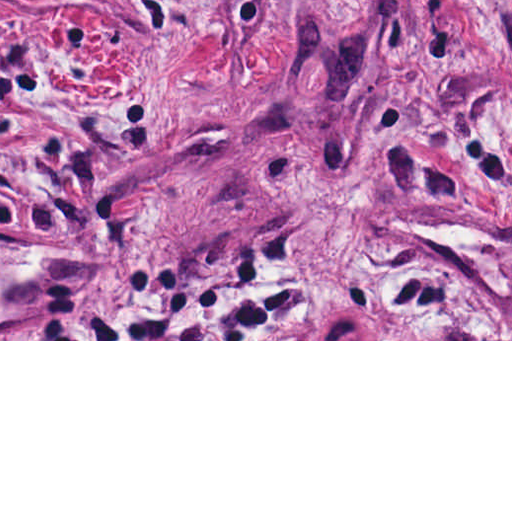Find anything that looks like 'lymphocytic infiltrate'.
I'll return each mask as SVG.
<instances>
[{"label":"lymphocytic infiltrate","mask_w":512,"mask_h":512,"mask_svg":"<svg viewBox=\"0 0 512 512\" xmlns=\"http://www.w3.org/2000/svg\"><path fill=\"white\" fill-rule=\"evenodd\" d=\"M73 339H294V307L282 284H191Z\"/></svg>","instance_id":"lymphocytic-infiltrate-1"}]
</instances>
